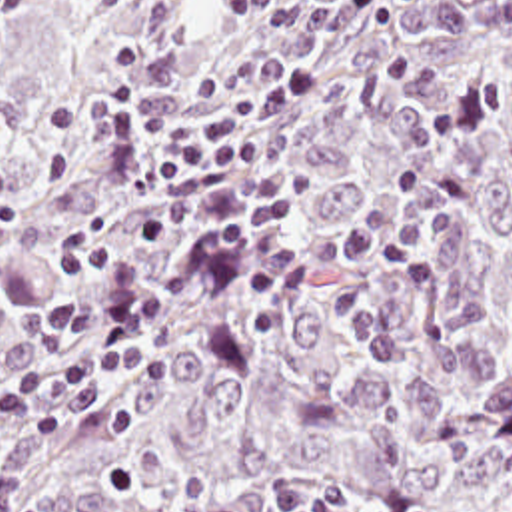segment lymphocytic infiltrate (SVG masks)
<instances>
[{
	"label": "lymphocytic infiltrate",
	"mask_w": 512,
	"mask_h": 512,
	"mask_svg": "<svg viewBox=\"0 0 512 512\" xmlns=\"http://www.w3.org/2000/svg\"><path fill=\"white\" fill-rule=\"evenodd\" d=\"M111 54L119 82L79 102L103 128L107 176L161 190L141 234L197 240L187 260L147 262L97 220L55 244L49 262L61 290L31 314L29 328L57 348L35 366L0 364V512H43L21 505V483L3 465L5 431L61 441L81 384L161 368L151 340L197 280H239L253 324L267 334L305 292L319 296L385 372L397 366L389 330L343 294L337 276L387 278L415 296L441 290L433 248L455 208L421 168L397 170L387 200L351 232L327 240L293 234L291 158L275 130L309 90L301 68L225 56L189 88L183 50L171 38L127 36Z\"/></svg>",
	"instance_id": "1"
}]
</instances>
